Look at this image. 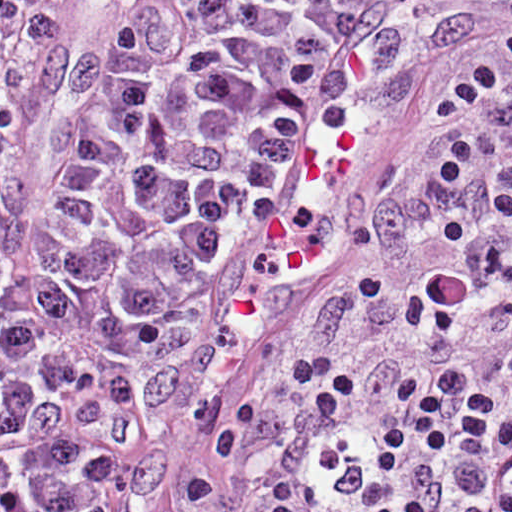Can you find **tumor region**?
Instances as JSON below:
<instances>
[{
	"mask_svg": "<svg viewBox=\"0 0 512 512\" xmlns=\"http://www.w3.org/2000/svg\"><path fill=\"white\" fill-rule=\"evenodd\" d=\"M417 512H512V271Z\"/></svg>",
	"mask_w": 512,
	"mask_h": 512,
	"instance_id": "obj_1",
	"label": "tumor region"
}]
</instances>
